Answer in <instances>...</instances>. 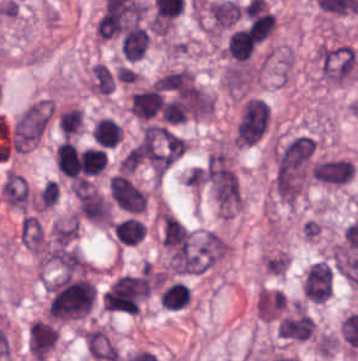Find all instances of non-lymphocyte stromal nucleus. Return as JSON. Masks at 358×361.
<instances>
[{
  "label": "non-lymphocyte stromal nucleus",
  "mask_w": 358,
  "mask_h": 361,
  "mask_svg": "<svg viewBox=\"0 0 358 361\" xmlns=\"http://www.w3.org/2000/svg\"><path fill=\"white\" fill-rule=\"evenodd\" d=\"M314 142L297 134L275 148L272 182L277 196L293 201L303 190L312 170Z\"/></svg>",
  "instance_id": "obj_1"
},
{
  "label": "non-lymphocyte stromal nucleus",
  "mask_w": 358,
  "mask_h": 361,
  "mask_svg": "<svg viewBox=\"0 0 358 361\" xmlns=\"http://www.w3.org/2000/svg\"><path fill=\"white\" fill-rule=\"evenodd\" d=\"M318 63L325 81L342 84L355 79L357 75L358 51L342 43L323 46L319 51Z\"/></svg>",
  "instance_id": "obj_2"
},
{
  "label": "non-lymphocyte stromal nucleus",
  "mask_w": 358,
  "mask_h": 361,
  "mask_svg": "<svg viewBox=\"0 0 358 361\" xmlns=\"http://www.w3.org/2000/svg\"><path fill=\"white\" fill-rule=\"evenodd\" d=\"M49 116V100H37L28 104L13 125L12 147L25 149L35 143Z\"/></svg>",
  "instance_id": "obj_3"
},
{
  "label": "non-lymphocyte stromal nucleus",
  "mask_w": 358,
  "mask_h": 361,
  "mask_svg": "<svg viewBox=\"0 0 358 361\" xmlns=\"http://www.w3.org/2000/svg\"><path fill=\"white\" fill-rule=\"evenodd\" d=\"M225 255V240L213 231L192 234L185 274H201Z\"/></svg>",
  "instance_id": "obj_4"
},
{
  "label": "non-lymphocyte stromal nucleus",
  "mask_w": 358,
  "mask_h": 361,
  "mask_svg": "<svg viewBox=\"0 0 358 361\" xmlns=\"http://www.w3.org/2000/svg\"><path fill=\"white\" fill-rule=\"evenodd\" d=\"M204 171L213 196L220 202H235L237 189L234 175L223 154H209Z\"/></svg>",
  "instance_id": "obj_5"
},
{
  "label": "non-lymphocyte stromal nucleus",
  "mask_w": 358,
  "mask_h": 361,
  "mask_svg": "<svg viewBox=\"0 0 358 361\" xmlns=\"http://www.w3.org/2000/svg\"><path fill=\"white\" fill-rule=\"evenodd\" d=\"M334 284V269L326 259L313 263L302 276L303 297L312 302H325Z\"/></svg>",
  "instance_id": "obj_6"
},
{
  "label": "non-lymphocyte stromal nucleus",
  "mask_w": 358,
  "mask_h": 361,
  "mask_svg": "<svg viewBox=\"0 0 358 361\" xmlns=\"http://www.w3.org/2000/svg\"><path fill=\"white\" fill-rule=\"evenodd\" d=\"M79 213L94 223H108L112 218L110 203L92 186L78 181L71 186Z\"/></svg>",
  "instance_id": "obj_7"
},
{
  "label": "non-lymphocyte stromal nucleus",
  "mask_w": 358,
  "mask_h": 361,
  "mask_svg": "<svg viewBox=\"0 0 358 361\" xmlns=\"http://www.w3.org/2000/svg\"><path fill=\"white\" fill-rule=\"evenodd\" d=\"M110 195L115 204L129 212H143L145 198L134 182L123 174L113 175L108 180Z\"/></svg>",
  "instance_id": "obj_8"
},
{
  "label": "non-lymphocyte stromal nucleus",
  "mask_w": 358,
  "mask_h": 361,
  "mask_svg": "<svg viewBox=\"0 0 358 361\" xmlns=\"http://www.w3.org/2000/svg\"><path fill=\"white\" fill-rule=\"evenodd\" d=\"M353 178V163L347 157H328L314 162V180L323 185L340 186Z\"/></svg>",
  "instance_id": "obj_9"
},
{
  "label": "non-lymphocyte stromal nucleus",
  "mask_w": 358,
  "mask_h": 361,
  "mask_svg": "<svg viewBox=\"0 0 358 361\" xmlns=\"http://www.w3.org/2000/svg\"><path fill=\"white\" fill-rule=\"evenodd\" d=\"M18 239L24 247L40 253L45 246L43 223L35 215L24 212L18 230Z\"/></svg>",
  "instance_id": "obj_10"
},
{
  "label": "non-lymphocyte stromal nucleus",
  "mask_w": 358,
  "mask_h": 361,
  "mask_svg": "<svg viewBox=\"0 0 358 361\" xmlns=\"http://www.w3.org/2000/svg\"><path fill=\"white\" fill-rule=\"evenodd\" d=\"M0 191L6 203L25 210L28 194L21 174L7 169Z\"/></svg>",
  "instance_id": "obj_11"
},
{
  "label": "non-lymphocyte stromal nucleus",
  "mask_w": 358,
  "mask_h": 361,
  "mask_svg": "<svg viewBox=\"0 0 358 361\" xmlns=\"http://www.w3.org/2000/svg\"><path fill=\"white\" fill-rule=\"evenodd\" d=\"M315 322L304 313L286 317L280 327V337L306 339L313 333Z\"/></svg>",
  "instance_id": "obj_12"
},
{
  "label": "non-lymphocyte stromal nucleus",
  "mask_w": 358,
  "mask_h": 361,
  "mask_svg": "<svg viewBox=\"0 0 358 361\" xmlns=\"http://www.w3.org/2000/svg\"><path fill=\"white\" fill-rule=\"evenodd\" d=\"M88 86L96 94H105L113 91L115 85V71L103 62H96L88 75Z\"/></svg>",
  "instance_id": "obj_13"
},
{
  "label": "non-lymphocyte stromal nucleus",
  "mask_w": 358,
  "mask_h": 361,
  "mask_svg": "<svg viewBox=\"0 0 358 361\" xmlns=\"http://www.w3.org/2000/svg\"><path fill=\"white\" fill-rule=\"evenodd\" d=\"M91 133L100 146L112 147L120 137V125L107 116H100L95 120Z\"/></svg>",
  "instance_id": "obj_14"
},
{
  "label": "non-lymphocyte stromal nucleus",
  "mask_w": 358,
  "mask_h": 361,
  "mask_svg": "<svg viewBox=\"0 0 358 361\" xmlns=\"http://www.w3.org/2000/svg\"><path fill=\"white\" fill-rule=\"evenodd\" d=\"M77 215H69L58 220L49 232V238L57 244H70L77 235Z\"/></svg>",
  "instance_id": "obj_15"
}]
</instances>
